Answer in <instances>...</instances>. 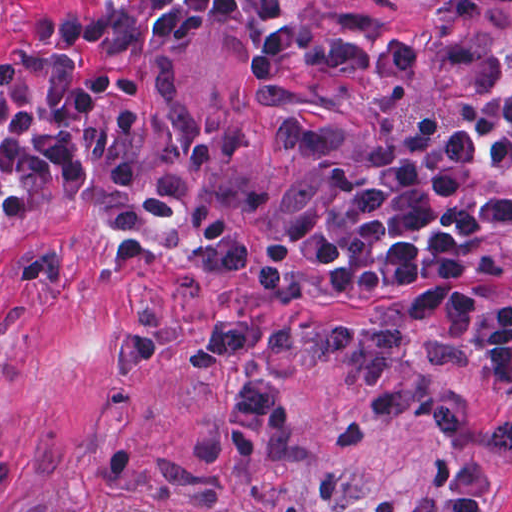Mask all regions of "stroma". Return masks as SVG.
Masks as SVG:
<instances>
[{
	"label": "stroma",
	"mask_w": 512,
	"mask_h": 512,
	"mask_svg": "<svg viewBox=\"0 0 512 512\" xmlns=\"http://www.w3.org/2000/svg\"><path fill=\"white\" fill-rule=\"evenodd\" d=\"M90 0H0V53ZM320 31L280 86L257 89V46L210 31L175 64L94 79L130 118L158 196L101 234L59 204H4L0 237V512H512V459L373 418L337 357L267 363L292 421L283 451L239 459L226 414L242 367L197 371L198 327L231 310L402 327L445 388L467 347L400 318L371 289L283 301L205 280V246L253 240L348 163L458 112L446 63L469 45L512 59V0H260ZM512 200V198L507 201ZM468 284L512 303V263Z\"/></svg>",
	"instance_id": "obj_1"
}]
</instances>
